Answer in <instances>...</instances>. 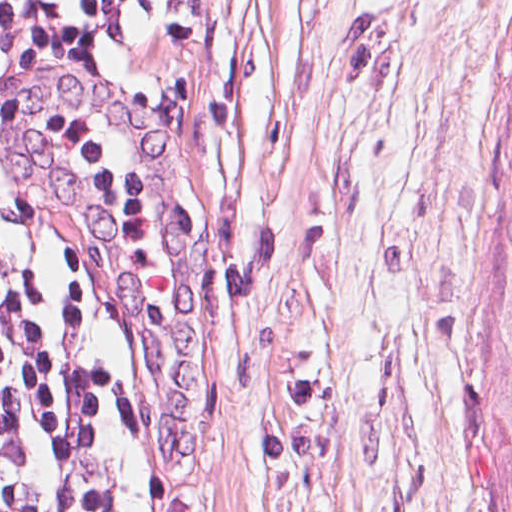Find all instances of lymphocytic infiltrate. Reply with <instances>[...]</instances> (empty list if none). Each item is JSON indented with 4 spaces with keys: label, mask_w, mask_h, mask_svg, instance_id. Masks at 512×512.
Returning <instances> with one entry per match:
<instances>
[{
    "label": "lymphocytic infiltrate",
    "mask_w": 512,
    "mask_h": 512,
    "mask_svg": "<svg viewBox=\"0 0 512 512\" xmlns=\"http://www.w3.org/2000/svg\"><path fill=\"white\" fill-rule=\"evenodd\" d=\"M136 0H0V22L100 47ZM51 321L47 286L0 257V512H58L48 405L22 348Z\"/></svg>",
    "instance_id": "f902f5d3"
}]
</instances>
